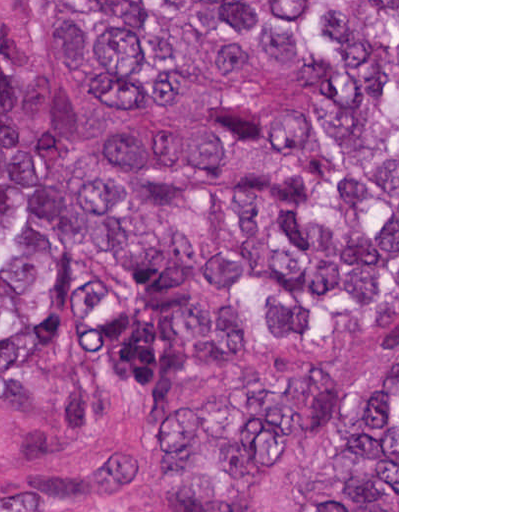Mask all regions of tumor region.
Instances as JSON below:
<instances>
[{"label":"tumor region","instance_id":"obj_1","mask_svg":"<svg viewBox=\"0 0 512 512\" xmlns=\"http://www.w3.org/2000/svg\"><path fill=\"white\" fill-rule=\"evenodd\" d=\"M53 41L93 99L102 166L199 227L208 281L168 224L118 206L42 48L0 58V403L45 373L64 427L98 431L264 339L302 355L397 329V0H62ZM162 436L183 512H241L330 437L280 512H397V352L357 404L281 361ZM153 508L143 457L0 502Z\"/></svg>","mask_w":512,"mask_h":512}]
</instances>
